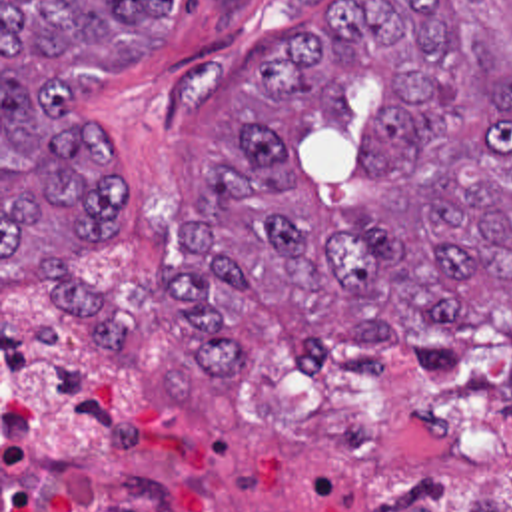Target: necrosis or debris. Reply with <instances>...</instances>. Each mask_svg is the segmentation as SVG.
Masks as SVG:
<instances>
[{
    "instance_id": "obj_1",
    "label": "necrosis or debris",
    "mask_w": 512,
    "mask_h": 512,
    "mask_svg": "<svg viewBox=\"0 0 512 512\" xmlns=\"http://www.w3.org/2000/svg\"><path fill=\"white\" fill-rule=\"evenodd\" d=\"M301 444L359 488L467 466L512 476V329L485 319L425 371L319 361L262 319L228 397L182 403L46 317L2 311V480L88 478L128 446Z\"/></svg>"
}]
</instances>
